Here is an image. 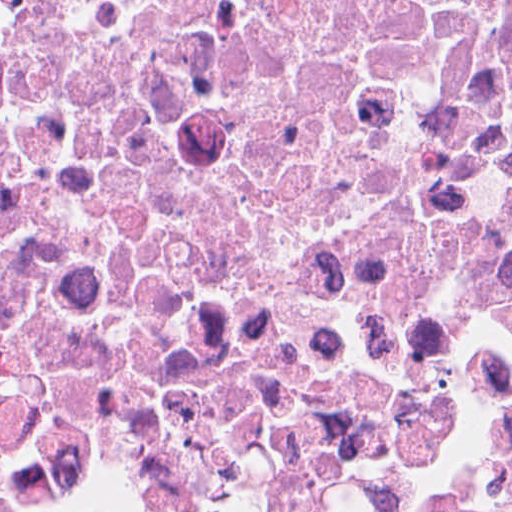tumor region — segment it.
<instances>
[{
    "instance_id": "tumor-region-1",
    "label": "tumor region",
    "mask_w": 512,
    "mask_h": 512,
    "mask_svg": "<svg viewBox=\"0 0 512 512\" xmlns=\"http://www.w3.org/2000/svg\"><path fill=\"white\" fill-rule=\"evenodd\" d=\"M0 512H102L95 510H15L0 505ZM461 512H512V442L505 448L498 487L479 497Z\"/></svg>"
}]
</instances>
